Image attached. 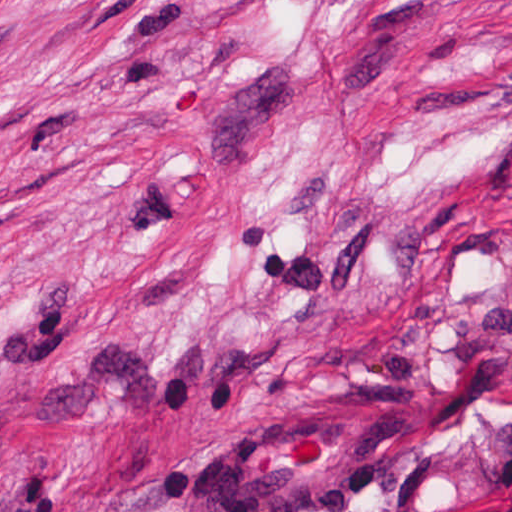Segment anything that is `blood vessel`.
<instances>
[{
  "label": "blood vessel",
  "mask_w": 512,
  "mask_h": 512,
  "mask_svg": "<svg viewBox=\"0 0 512 512\" xmlns=\"http://www.w3.org/2000/svg\"><path fill=\"white\" fill-rule=\"evenodd\" d=\"M386 432L344 409H312L235 436L205 462L202 512H338L377 466Z\"/></svg>",
  "instance_id": "obj_1"
}]
</instances>
